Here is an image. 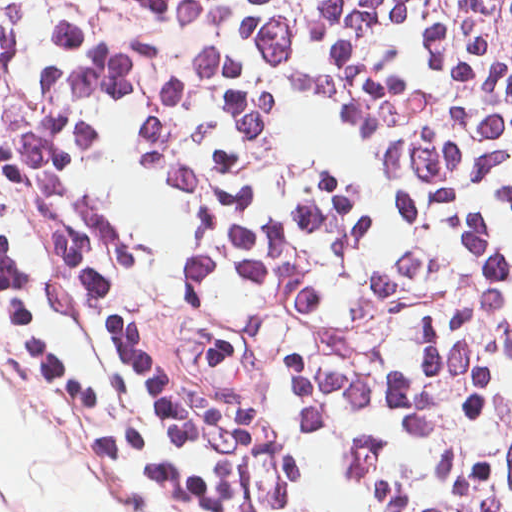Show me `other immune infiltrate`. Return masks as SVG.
<instances>
[{
    "label": "other immune infiltrate",
    "mask_w": 512,
    "mask_h": 512,
    "mask_svg": "<svg viewBox=\"0 0 512 512\" xmlns=\"http://www.w3.org/2000/svg\"><path fill=\"white\" fill-rule=\"evenodd\" d=\"M0 207L58 355L148 512H277L1 77Z\"/></svg>",
    "instance_id": "obj_1"
}]
</instances>
